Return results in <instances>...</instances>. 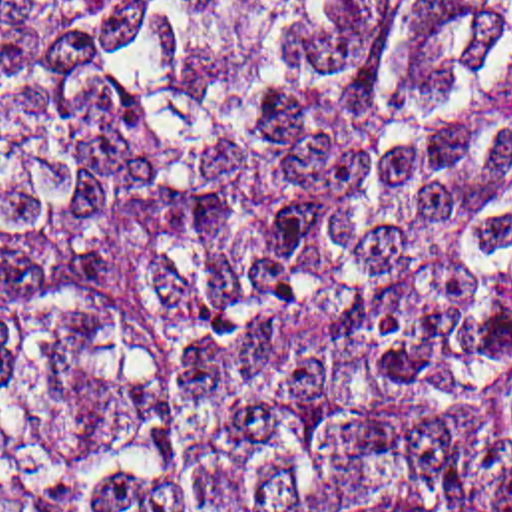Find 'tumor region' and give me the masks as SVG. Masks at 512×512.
I'll return each instance as SVG.
<instances>
[{
	"mask_svg": "<svg viewBox=\"0 0 512 512\" xmlns=\"http://www.w3.org/2000/svg\"><path fill=\"white\" fill-rule=\"evenodd\" d=\"M0 512H512V0H0Z\"/></svg>",
	"mask_w": 512,
	"mask_h": 512,
	"instance_id": "1",
	"label": "tumor region"
}]
</instances>
